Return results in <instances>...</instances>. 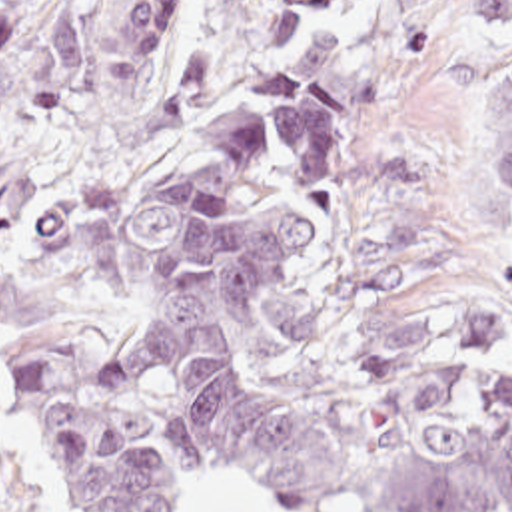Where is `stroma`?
Returning <instances> with one entry per match:
<instances>
[{
	"instance_id": "obj_1",
	"label": "stroma",
	"mask_w": 512,
	"mask_h": 512,
	"mask_svg": "<svg viewBox=\"0 0 512 512\" xmlns=\"http://www.w3.org/2000/svg\"><path fill=\"white\" fill-rule=\"evenodd\" d=\"M35 7L51 0H33ZM85 17V81L29 115L0 97V411L7 454L35 512H69L9 399L17 341L71 339L107 387L123 335L99 285V231L263 73L287 71L271 23L299 0H183L155 75L207 49V81L175 127H129L109 97L105 39L127 0H71ZM345 29L378 71L376 99L349 111L353 163L335 223L301 275L269 291L277 383L289 397L357 373L422 307L512 315V215L502 203L498 127L512 29L482 27L470 0H369ZM185 512H283L249 482L191 488ZM333 512H363L343 504Z\"/></svg>"
}]
</instances>
